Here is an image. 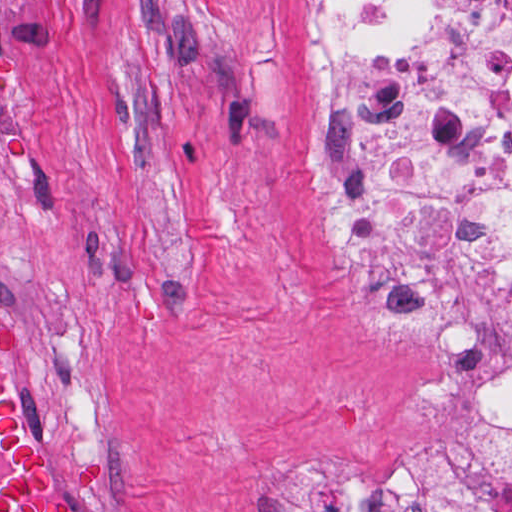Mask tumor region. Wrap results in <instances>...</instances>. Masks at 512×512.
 <instances>
[{
    "mask_svg": "<svg viewBox=\"0 0 512 512\" xmlns=\"http://www.w3.org/2000/svg\"><path fill=\"white\" fill-rule=\"evenodd\" d=\"M25 343L21 326L0 329V512H74L72 503L55 496L43 448L16 426L18 392L3 363ZM67 482L76 498H101L105 464L79 455L68 465Z\"/></svg>",
    "mask_w": 512,
    "mask_h": 512,
    "instance_id": "1",
    "label": "tumor region"
}]
</instances>
